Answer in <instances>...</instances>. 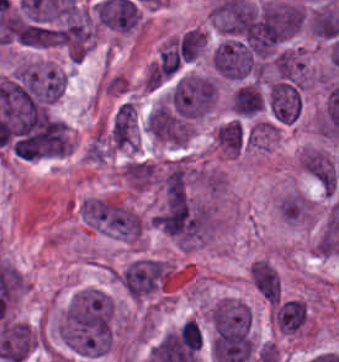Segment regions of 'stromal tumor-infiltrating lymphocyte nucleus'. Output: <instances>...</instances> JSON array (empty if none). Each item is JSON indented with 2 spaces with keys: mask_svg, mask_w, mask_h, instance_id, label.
<instances>
[{
  "mask_svg": "<svg viewBox=\"0 0 339 362\" xmlns=\"http://www.w3.org/2000/svg\"><path fill=\"white\" fill-rule=\"evenodd\" d=\"M177 336L184 350L199 351L204 340L203 333L194 320H187L180 327Z\"/></svg>",
  "mask_w": 339,
  "mask_h": 362,
  "instance_id": "bc302bb0",
  "label": "stromal tumor-infiltrating lymphocyte nucleus"
}]
</instances>
